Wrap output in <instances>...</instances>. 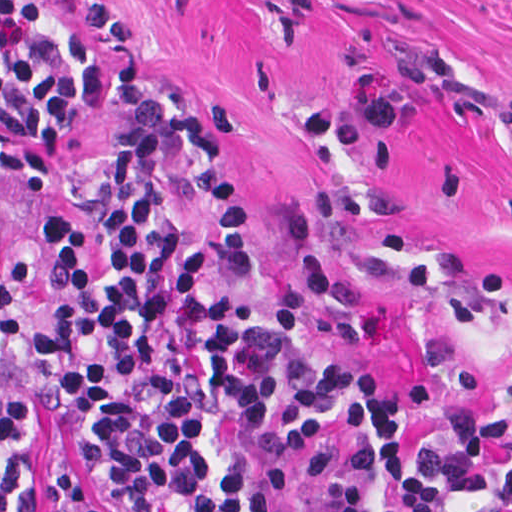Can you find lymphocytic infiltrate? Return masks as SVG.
I'll return each instance as SVG.
<instances>
[{"label": "lymphocytic infiltrate", "mask_w": 512, "mask_h": 512, "mask_svg": "<svg viewBox=\"0 0 512 512\" xmlns=\"http://www.w3.org/2000/svg\"><path fill=\"white\" fill-rule=\"evenodd\" d=\"M107 103L60 8L0 0V194L45 182ZM49 256L48 290L0 270V512H29L47 413L108 512H442L443 490L512 507V413L456 401L425 463L385 378L219 283L251 275V226L199 109L166 99L67 159ZM43 503L92 512L45 456Z\"/></svg>", "instance_id": "lymphocytic-infiltrate-1"}]
</instances>
